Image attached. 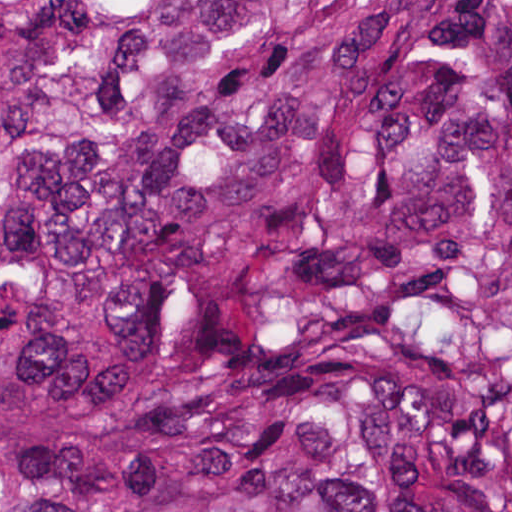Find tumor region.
Wrapping results in <instances>:
<instances>
[{
	"instance_id": "obj_1",
	"label": "tumor region",
	"mask_w": 512,
	"mask_h": 512,
	"mask_svg": "<svg viewBox=\"0 0 512 512\" xmlns=\"http://www.w3.org/2000/svg\"><path fill=\"white\" fill-rule=\"evenodd\" d=\"M0 512H512V1H0Z\"/></svg>"
}]
</instances>
